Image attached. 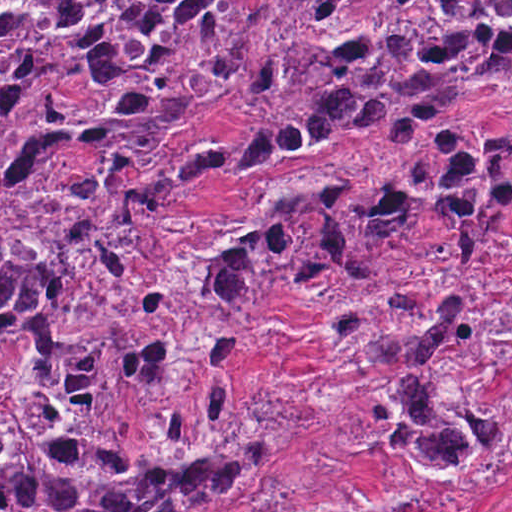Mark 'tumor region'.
<instances>
[{
    "mask_svg": "<svg viewBox=\"0 0 512 512\" xmlns=\"http://www.w3.org/2000/svg\"><path fill=\"white\" fill-rule=\"evenodd\" d=\"M256 34L257 1H0V512H227L267 482L298 413L234 385L286 265L294 297L348 285L323 344L365 356L367 431L488 500L512 275L478 272L512 220V124L462 144L448 118L512 95V1H283L239 173L368 138L383 175L267 185L157 263L220 152L144 164ZM86 257L71 325L23 333Z\"/></svg>",
    "mask_w": 512,
    "mask_h": 512,
    "instance_id": "obj_1",
    "label": "tumor region"
}]
</instances>
